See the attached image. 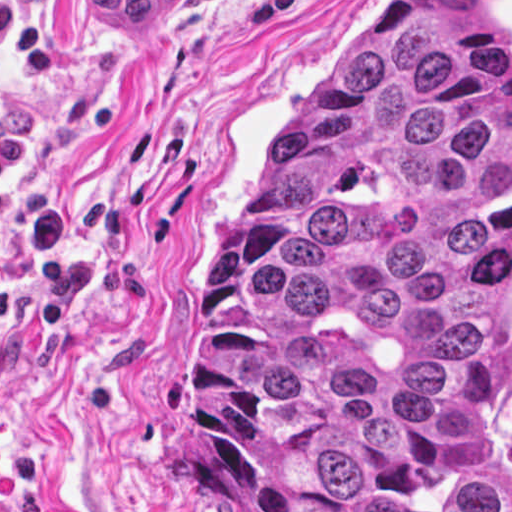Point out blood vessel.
<instances>
[{
	"mask_svg": "<svg viewBox=\"0 0 512 512\" xmlns=\"http://www.w3.org/2000/svg\"><path fill=\"white\" fill-rule=\"evenodd\" d=\"M173 0H81L86 9L105 25L140 28Z\"/></svg>",
	"mask_w": 512,
	"mask_h": 512,
	"instance_id": "blood-vessel-1",
	"label": "blood vessel"
}]
</instances>
